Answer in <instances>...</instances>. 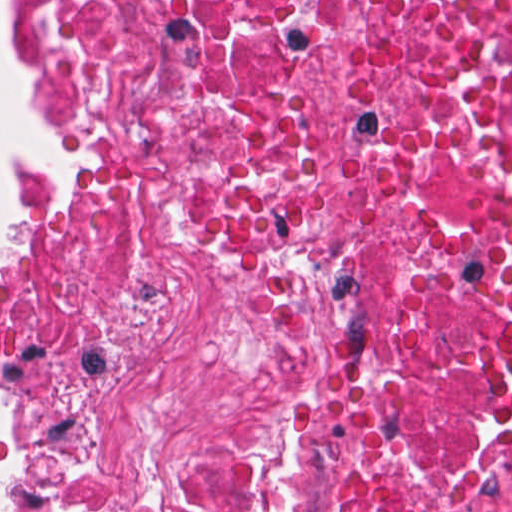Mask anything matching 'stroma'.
<instances>
[{
	"mask_svg": "<svg viewBox=\"0 0 512 512\" xmlns=\"http://www.w3.org/2000/svg\"><path fill=\"white\" fill-rule=\"evenodd\" d=\"M8 45L24 76L36 88L32 69V24L26 0H8ZM28 169L20 156L5 160V226L0 234V286L19 249V207ZM14 437V413L0 404V468ZM3 512H93V488L72 472L47 466L37 484L0 472Z\"/></svg>",
	"mask_w": 512,
	"mask_h": 512,
	"instance_id": "obj_1",
	"label": "stroma"
}]
</instances>
